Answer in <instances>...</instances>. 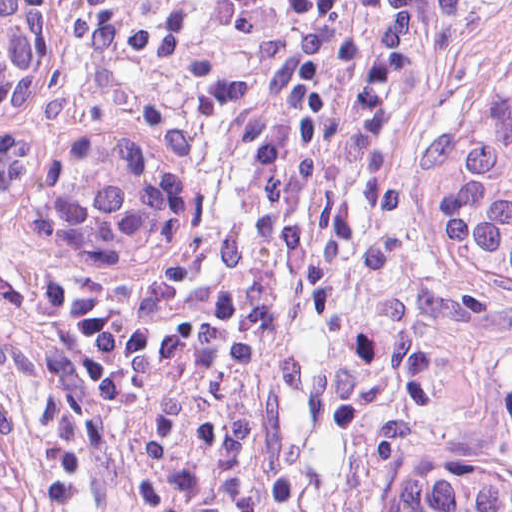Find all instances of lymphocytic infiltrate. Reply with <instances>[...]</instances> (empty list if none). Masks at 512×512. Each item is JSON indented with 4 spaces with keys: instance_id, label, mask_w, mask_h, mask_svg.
<instances>
[{
    "instance_id": "lymphocytic-infiltrate-1",
    "label": "lymphocytic infiltrate",
    "mask_w": 512,
    "mask_h": 512,
    "mask_svg": "<svg viewBox=\"0 0 512 512\" xmlns=\"http://www.w3.org/2000/svg\"><path fill=\"white\" fill-rule=\"evenodd\" d=\"M75 7L84 33L118 61L88 1ZM319 195L320 159L299 197L269 320ZM194 268L156 327L114 425L174 322ZM511 374L508 306L491 284L437 255L256 471L257 512H370L402 472L473 425Z\"/></svg>"
}]
</instances>
